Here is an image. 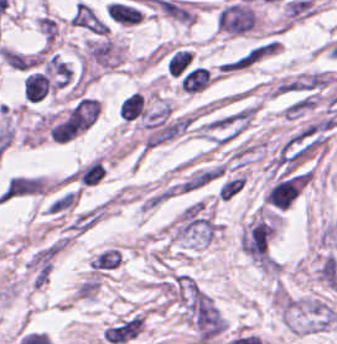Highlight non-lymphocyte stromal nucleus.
Returning a JSON list of instances; mask_svg holds the SVG:
<instances>
[{"mask_svg": "<svg viewBox=\"0 0 337 344\" xmlns=\"http://www.w3.org/2000/svg\"><path fill=\"white\" fill-rule=\"evenodd\" d=\"M139 334V314H126L106 326L101 333L105 344H127Z\"/></svg>", "mask_w": 337, "mask_h": 344, "instance_id": "non-lymphocyte-stromal-nucleus-1", "label": "non-lymphocyte stromal nucleus"}, {"mask_svg": "<svg viewBox=\"0 0 337 344\" xmlns=\"http://www.w3.org/2000/svg\"><path fill=\"white\" fill-rule=\"evenodd\" d=\"M69 25L94 34H107V24L86 3L80 1L73 9Z\"/></svg>", "mask_w": 337, "mask_h": 344, "instance_id": "non-lymphocyte-stromal-nucleus-2", "label": "non-lymphocyte stromal nucleus"}, {"mask_svg": "<svg viewBox=\"0 0 337 344\" xmlns=\"http://www.w3.org/2000/svg\"><path fill=\"white\" fill-rule=\"evenodd\" d=\"M122 253L116 246H108L99 251L90 261L89 270L95 273H105L115 270L121 262Z\"/></svg>", "mask_w": 337, "mask_h": 344, "instance_id": "non-lymphocyte-stromal-nucleus-3", "label": "non-lymphocyte stromal nucleus"}, {"mask_svg": "<svg viewBox=\"0 0 337 344\" xmlns=\"http://www.w3.org/2000/svg\"><path fill=\"white\" fill-rule=\"evenodd\" d=\"M245 183L246 178L244 174L226 179L219 188L218 199H220L221 201H229L241 192Z\"/></svg>", "mask_w": 337, "mask_h": 344, "instance_id": "non-lymphocyte-stromal-nucleus-4", "label": "non-lymphocyte stromal nucleus"}]
</instances>
